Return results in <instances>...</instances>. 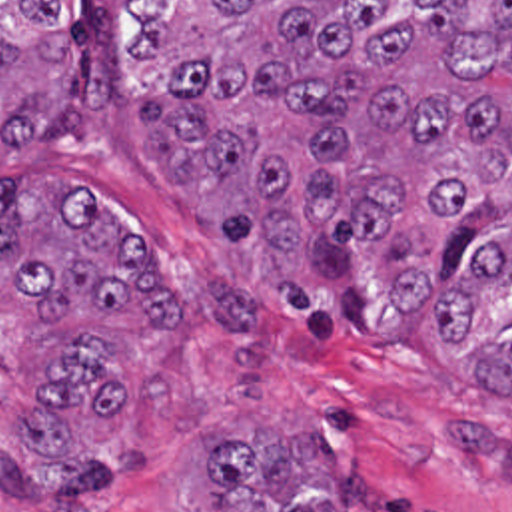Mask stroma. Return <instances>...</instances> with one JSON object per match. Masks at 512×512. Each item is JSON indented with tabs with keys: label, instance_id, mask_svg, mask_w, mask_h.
Instances as JSON below:
<instances>
[{
	"label": "stroma",
	"instance_id": "obj_1",
	"mask_svg": "<svg viewBox=\"0 0 512 512\" xmlns=\"http://www.w3.org/2000/svg\"><path fill=\"white\" fill-rule=\"evenodd\" d=\"M39 173L93 193L137 229L159 269L195 303L193 333H123L101 317L39 311L0 273V460H73L137 446L139 478L75 494L63 512H211L201 448L215 438L305 434L329 454L345 512H512V392L488 398L476 376L492 337L512 325V281L496 309L448 356L442 283L383 329H305L267 283L259 257L213 235L191 193L141 151L131 105L93 121L87 143H33L0 157V185ZM71 335H105L123 374L115 424L75 412L73 452L21 450L19 418L35 366ZM0 512H43L0 488Z\"/></svg>",
	"mask_w": 512,
	"mask_h": 512
}]
</instances>
